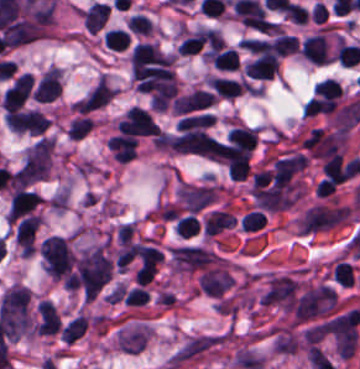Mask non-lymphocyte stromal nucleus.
<instances>
[{"instance_id": "dd21d789", "label": "non-lymphocyte stromal nucleus", "mask_w": 360, "mask_h": 369, "mask_svg": "<svg viewBox=\"0 0 360 369\" xmlns=\"http://www.w3.org/2000/svg\"><path fill=\"white\" fill-rule=\"evenodd\" d=\"M231 337L227 328L191 333L168 356L165 365L170 369L184 368L218 351Z\"/></svg>"}, {"instance_id": "a72fc3eb", "label": "non-lymphocyte stromal nucleus", "mask_w": 360, "mask_h": 369, "mask_svg": "<svg viewBox=\"0 0 360 369\" xmlns=\"http://www.w3.org/2000/svg\"><path fill=\"white\" fill-rule=\"evenodd\" d=\"M51 155L52 140L42 136L25 152L15 177L20 182H31L47 177Z\"/></svg>"}, {"instance_id": "3746e769", "label": "non-lymphocyte stromal nucleus", "mask_w": 360, "mask_h": 369, "mask_svg": "<svg viewBox=\"0 0 360 369\" xmlns=\"http://www.w3.org/2000/svg\"><path fill=\"white\" fill-rule=\"evenodd\" d=\"M43 264L52 279H60L69 274L76 257L65 238L51 235L40 244Z\"/></svg>"}, {"instance_id": "fc2b8d12", "label": "non-lymphocyte stromal nucleus", "mask_w": 360, "mask_h": 369, "mask_svg": "<svg viewBox=\"0 0 360 369\" xmlns=\"http://www.w3.org/2000/svg\"><path fill=\"white\" fill-rule=\"evenodd\" d=\"M5 124L16 132L41 134L50 119L35 108L10 109L5 114Z\"/></svg>"}, {"instance_id": "81446118", "label": "non-lymphocyte stromal nucleus", "mask_w": 360, "mask_h": 369, "mask_svg": "<svg viewBox=\"0 0 360 369\" xmlns=\"http://www.w3.org/2000/svg\"><path fill=\"white\" fill-rule=\"evenodd\" d=\"M39 222L40 219L32 213L18 222L14 240L20 248H34Z\"/></svg>"}]
</instances>
